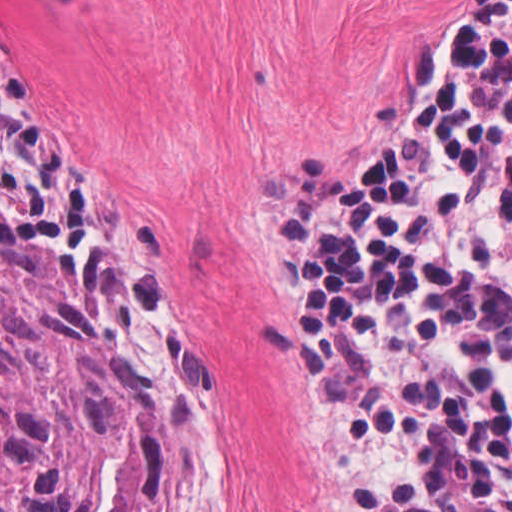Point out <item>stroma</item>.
I'll use <instances>...</instances> for the list:
<instances>
[{
    "label": "stroma",
    "instance_id": "1",
    "mask_svg": "<svg viewBox=\"0 0 512 512\" xmlns=\"http://www.w3.org/2000/svg\"><path fill=\"white\" fill-rule=\"evenodd\" d=\"M469 0H0V54L73 202L0 186L165 413L198 512H343L279 207L387 144Z\"/></svg>",
    "mask_w": 512,
    "mask_h": 512
}]
</instances>
